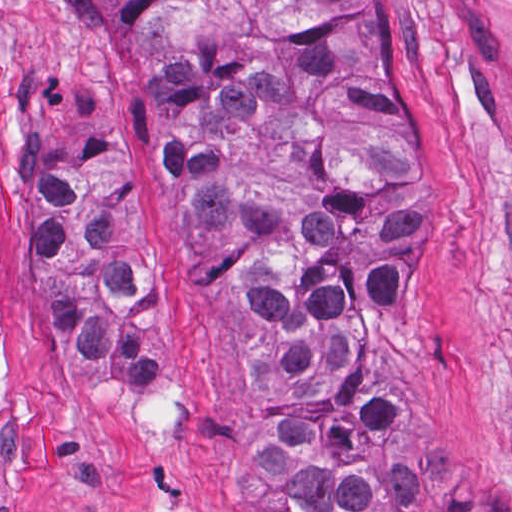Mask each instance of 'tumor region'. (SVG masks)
Returning <instances> with one entry per match:
<instances>
[{
  "instance_id": "obj_1",
  "label": "tumor region",
  "mask_w": 512,
  "mask_h": 512,
  "mask_svg": "<svg viewBox=\"0 0 512 512\" xmlns=\"http://www.w3.org/2000/svg\"><path fill=\"white\" fill-rule=\"evenodd\" d=\"M83 69L134 104L186 248L252 370L249 458L269 512H512L421 435L423 267L438 143L404 0H43ZM121 122L30 75L19 182L48 344L151 390L156 262Z\"/></svg>"
}]
</instances>
